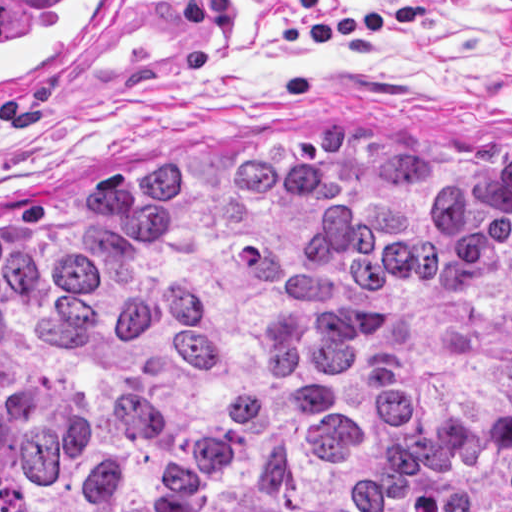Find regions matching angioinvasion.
Masks as SVG:
<instances>
[{
    "mask_svg": "<svg viewBox=\"0 0 512 512\" xmlns=\"http://www.w3.org/2000/svg\"><path fill=\"white\" fill-rule=\"evenodd\" d=\"M129 0H0V97H59L108 61Z\"/></svg>",
    "mask_w": 512,
    "mask_h": 512,
    "instance_id": "1",
    "label": "angioinvasion"
}]
</instances>
